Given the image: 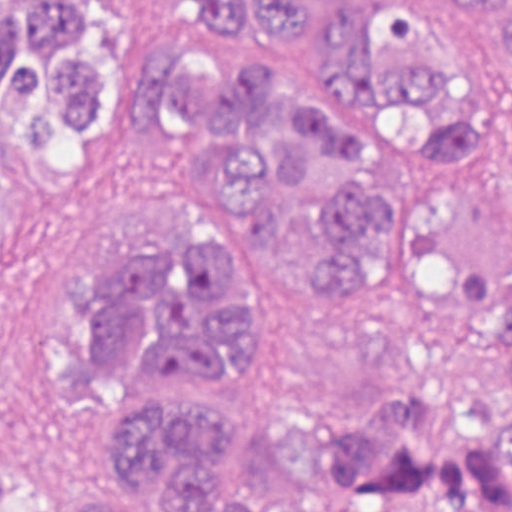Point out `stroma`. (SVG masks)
I'll return each instance as SVG.
<instances>
[{
  "mask_svg": "<svg viewBox=\"0 0 512 512\" xmlns=\"http://www.w3.org/2000/svg\"><path fill=\"white\" fill-rule=\"evenodd\" d=\"M214 46L205 21L163 33L139 79L168 53L190 77ZM489 86L512 109V84ZM182 166L174 128L135 119L127 145L80 192L13 232L0 266V472L59 481L85 461L60 383L64 325L81 295L72 271L102 278L118 257L166 243V198Z\"/></svg>",
  "mask_w": 512,
  "mask_h": 512,
  "instance_id": "1",
  "label": "stroma"
}]
</instances>
